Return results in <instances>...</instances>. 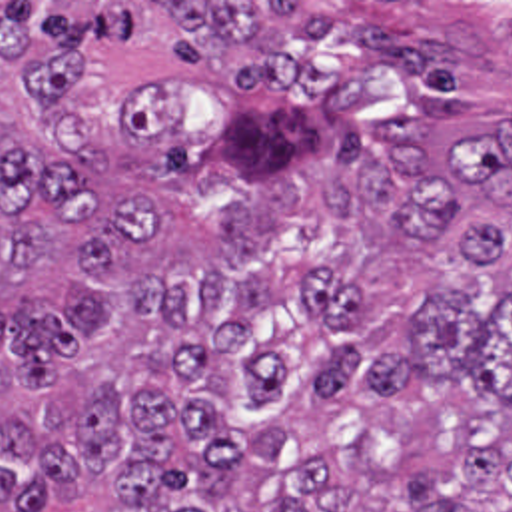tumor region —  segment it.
Returning <instances> with one entry per match:
<instances>
[{"mask_svg":"<svg viewBox=\"0 0 512 512\" xmlns=\"http://www.w3.org/2000/svg\"><path fill=\"white\" fill-rule=\"evenodd\" d=\"M0 512H512L511 2H0Z\"/></svg>","mask_w":512,"mask_h":512,"instance_id":"obj_1","label":"tumor region"}]
</instances>
